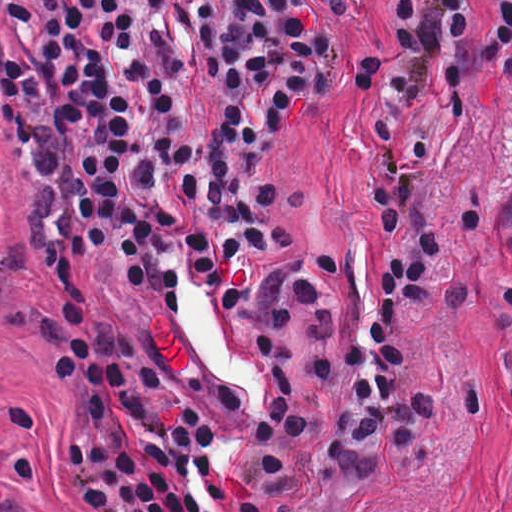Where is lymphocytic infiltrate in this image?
I'll use <instances>...</instances> for the list:
<instances>
[{"instance_id":"1","label":"lymphocytic infiltrate","mask_w":512,"mask_h":512,"mask_svg":"<svg viewBox=\"0 0 512 512\" xmlns=\"http://www.w3.org/2000/svg\"><path fill=\"white\" fill-rule=\"evenodd\" d=\"M341 2L343 0H330ZM173 10L218 105L206 138L183 133L189 66L166 31ZM400 43L359 68L369 111L387 107L405 135L430 107L472 101L475 84L512 40L486 41L475 0H393ZM333 41L306 0H0V104L30 166L31 228L55 294L46 345L64 410L65 447L79 483L78 512H271L292 490L290 461L313 435L316 407L292 372V325H310V370L331 379L338 342L311 264L252 261L285 244L280 200L255 176L285 124L318 90ZM512 92V60L494 95ZM388 236L431 221L451 194L422 191L442 145L439 111L396 154L379 126ZM468 234L492 219L472 194ZM115 252L134 293L205 325L208 362L233 416L250 430L241 469L247 497L213 467L214 430L177 400L157 410L159 371L134 333L97 315L81 280L93 251ZM444 265L435 234L377 261L369 323L347 348L348 394L325 453L341 480L373 487L391 451L423 468L439 461L449 412L482 421L485 386L430 377L415 345ZM509 310L512 294L501 298Z\"/></svg>"}]
</instances>
